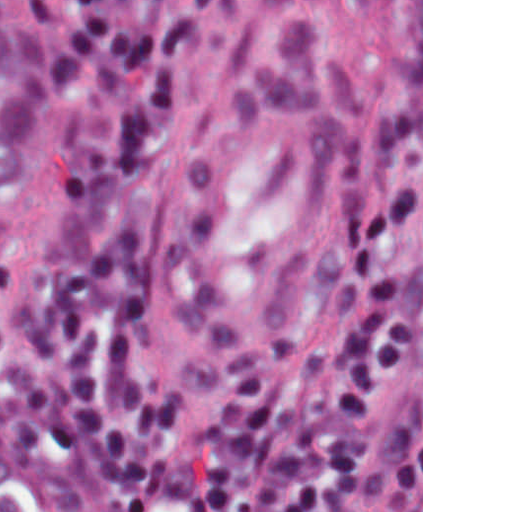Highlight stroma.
<instances>
[{"instance_id": "obj_1", "label": "stroma", "mask_w": 512, "mask_h": 512, "mask_svg": "<svg viewBox=\"0 0 512 512\" xmlns=\"http://www.w3.org/2000/svg\"><path fill=\"white\" fill-rule=\"evenodd\" d=\"M231 1L178 84L153 147L137 249L157 365L187 417L261 378L294 403V509L423 512V0ZM256 1H387L394 57L311 281L257 341L215 343L179 306V239L230 111ZM0 489L14 512H93L100 482L0 418Z\"/></svg>"}]
</instances>
